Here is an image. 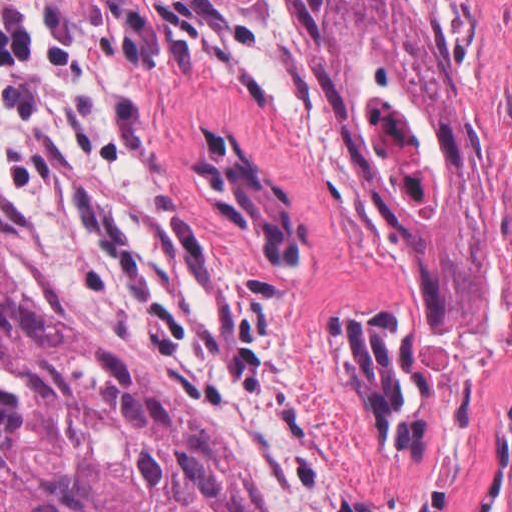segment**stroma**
I'll list each match as a JSON object with an SVG mask.
<instances>
[{"instance_id":"obj_1","label":"stroma","mask_w":512,"mask_h":512,"mask_svg":"<svg viewBox=\"0 0 512 512\" xmlns=\"http://www.w3.org/2000/svg\"><path fill=\"white\" fill-rule=\"evenodd\" d=\"M490 158V324L431 332L427 283L325 107L300 0H57L0 86L16 273L66 330L166 382L265 512H512V0H393ZM243 145L305 229L272 265L193 168ZM396 305L430 361L412 452L369 424L328 325Z\"/></svg>"}]
</instances>
